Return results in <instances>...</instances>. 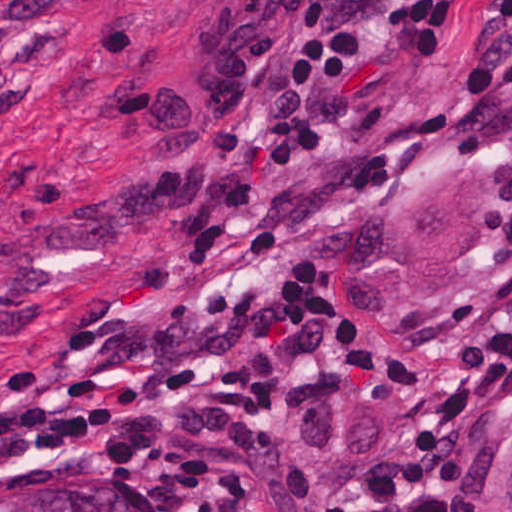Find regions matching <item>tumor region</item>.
<instances>
[{
    "instance_id": "obj_1",
    "label": "tumor region",
    "mask_w": 512,
    "mask_h": 512,
    "mask_svg": "<svg viewBox=\"0 0 512 512\" xmlns=\"http://www.w3.org/2000/svg\"><path fill=\"white\" fill-rule=\"evenodd\" d=\"M504 243V168L446 165L361 225L355 290L371 311H447L492 272ZM1 512L150 510L131 480L62 474L1 501Z\"/></svg>"
}]
</instances>
